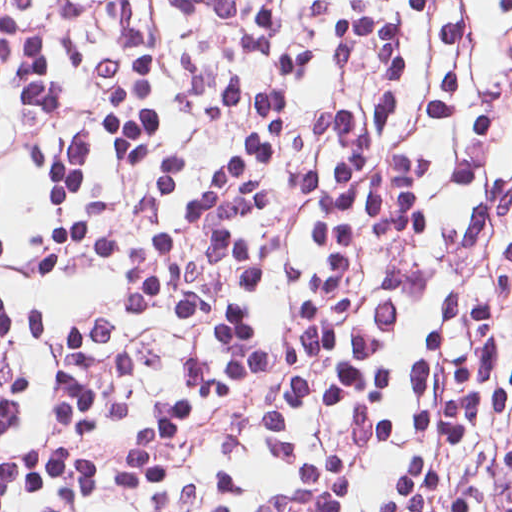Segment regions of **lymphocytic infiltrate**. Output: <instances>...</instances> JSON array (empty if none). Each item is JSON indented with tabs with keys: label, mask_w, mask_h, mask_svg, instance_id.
Wrapping results in <instances>:
<instances>
[{
	"label": "lymphocytic infiltrate",
	"mask_w": 512,
	"mask_h": 512,
	"mask_svg": "<svg viewBox=\"0 0 512 512\" xmlns=\"http://www.w3.org/2000/svg\"><path fill=\"white\" fill-rule=\"evenodd\" d=\"M0 512H512V0H0Z\"/></svg>",
	"instance_id": "1"
}]
</instances>
